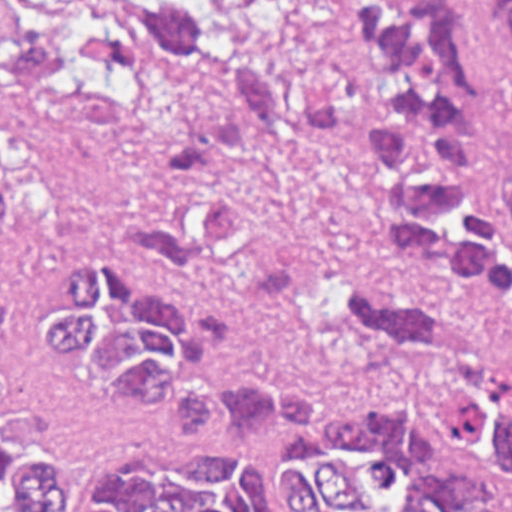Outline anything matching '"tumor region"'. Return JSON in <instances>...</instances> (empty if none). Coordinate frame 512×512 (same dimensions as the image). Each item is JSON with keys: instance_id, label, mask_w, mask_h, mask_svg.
I'll use <instances>...</instances> for the list:
<instances>
[{"instance_id": "e687c5a6", "label": "tumor region", "mask_w": 512, "mask_h": 512, "mask_svg": "<svg viewBox=\"0 0 512 512\" xmlns=\"http://www.w3.org/2000/svg\"><path fill=\"white\" fill-rule=\"evenodd\" d=\"M53 0L0 37V82L94 112H159L162 157L126 207L129 254H74L27 341L93 394L182 425L89 481L0 439V512H512V160L477 0ZM512 29V0H491ZM354 156L399 274L325 298L356 352L341 387L261 376L152 264L217 272L255 232L231 188L264 145ZM152 264H150V263Z\"/></svg>"}]
</instances>
